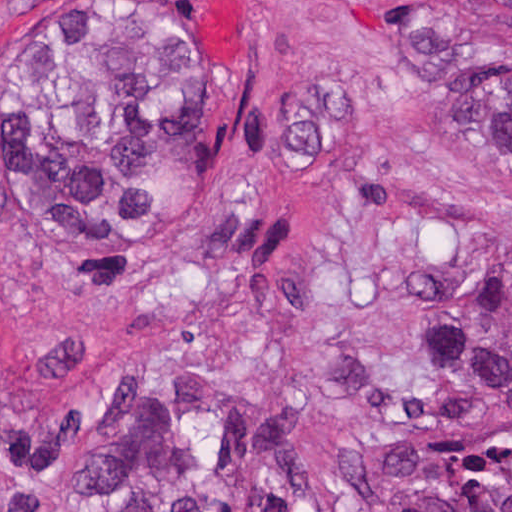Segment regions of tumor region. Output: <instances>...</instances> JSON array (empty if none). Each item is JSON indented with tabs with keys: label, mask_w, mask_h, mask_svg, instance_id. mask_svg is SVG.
I'll list each match as a JSON object with an SVG mask.
<instances>
[{
	"label": "tumor region",
	"mask_w": 512,
	"mask_h": 512,
	"mask_svg": "<svg viewBox=\"0 0 512 512\" xmlns=\"http://www.w3.org/2000/svg\"><path fill=\"white\" fill-rule=\"evenodd\" d=\"M512 26V0H485ZM407 53L456 111L476 159L512 180V67L481 59L451 13H405ZM207 69L198 40L51 34L27 60L32 216L79 246L165 235L201 207ZM446 388L497 421L493 442L398 450L337 512H512V268L462 292ZM125 443L0 491V512H216L212 465L177 435Z\"/></svg>",
	"instance_id": "e687c5a6"
}]
</instances>
